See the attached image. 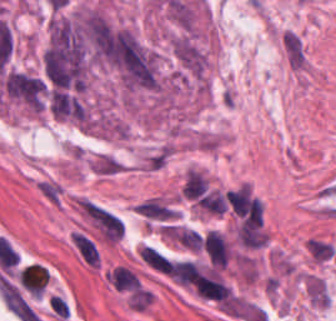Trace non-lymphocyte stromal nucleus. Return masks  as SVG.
<instances>
[{"instance_id": "6", "label": "non-lymphocyte stromal nucleus", "mask_w": 336, "mask_h": 321, "mask_svg": "<svg viewBox=\"0 0 336 321\" xmlns=\"http://www.w3.org/2000/svg\"><path fill=\"white\" fill-rule=\"evenodd\" d=\"M307 253L316 263H327L336 256V249L326 240L312 238L307 244Z\"/></svg>"}, {"instance_id": "3", "label": "non-lymphocyte stromal nucleus", "mask_w": 336, "mask_h": 321, "mask_svg": "<svg viewBox=\"0 0 336 321\" xmlns=\"http://www.w3.org/2000/svg\"><path fill=\"white\" fill-rule=\"evenodd\" d=\"M224 199L233 214L248 215L254 204L249 183H242L224 192Z\"/></svg>"}, {"instance_id": "4", "label": "non-lymphocyte stromal nucleus", "mask_w": 336, "mask_h": 321, "mask_svg": "<svg viewBox=\"0 0 336 321\" xmlns=\"http://www.w3.org/2000/svg\"><path fill=\"white\" fill-rule=\"evenodd\" d=\"M208 180L200 172L189 168L184 174L180 196L185 199L201 200L207 191Z\"/></svg>"}, {"instance_id": "5", "label": "non-lymphocyte stromal nucleus", "mask_w": 336, "mask_h": 321, "mask_svg": "<svg viewBox=\"0 0 336 321\" xmlns=\"http://www.w3.org/2000/svg\"><path fill=\"white\" fill-rule=\"evenodd\" d=\"M282 46L292 66H304L303 49L297 31H283Z\"/></svg>"}, {"instance_id": "1", "label": "non-lymphocyte stromal nucleus", "mask_w": 336, "mask_h": 321, "mask_svg": "<svg viewBox=\"0 0 336 321\" xmlns=\"http://www.w3.org/2000/svg\"><path fill=\"white\" fill-rule=\"evenodd\" d=\"M77 204L102 240L112 244L119 240L123 223L116 215L84 199H77Z\"/></svg>"}, {"instance_id": "2", "label": "non-lymphocyte stromal nucleus", "mask_w": 336, "mask_h": 321, "mask_svg": "<svg viewBox=\"0 0 336 321\" xmlns=\"http://www.w3.org/2000/svg\"><path fill=\"white\" fill-rule=\"evenodd\" d=\"M202 243L208 260L214 267H228L230 246L223 234L211 229L205 234Z\"/></svg>"}]
</instances>
